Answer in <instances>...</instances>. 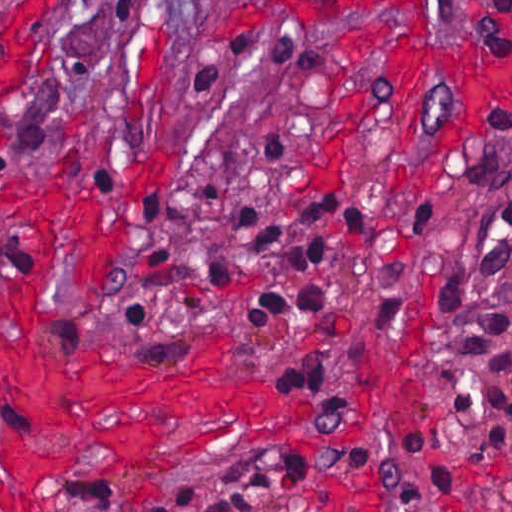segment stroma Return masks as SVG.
Returning <instances> with one entry per match:
<instances>
[{"label":"stroma","mask_w":512,"mask_h":512,"mask_svg":"<svg viewBox=\"0 0 512 512\" xmlns=\"http://www.w3.org/2000/svg\"><path fill=\"white\" fill-rule=\"evenodd\" d=\"M237 1L0 0V180L96 194L105 214L126 217L123 248L100 284L76 283L67 250L58 249L51 266L57 307L40 321L37 341L152 368L189 366L204 343L229 341L238 355L220 381L261 383L309 403L310 424L322 429L358 428L367 393L369 434L329 453L296 445L245 450L229 438L172 471L81 475L69 468L42 479L43 511L156 512L161 495L224 467L303 457L324 474L291 483L285 512H441L424 474L412 473L392 494L375 480L380 461L418 426L437 439L480 512H512V478L501 458L512 456V440L501 456L483 442L455 391V366L471 352L469 325L512 191V140L502 138L512 129V104L489 112L444 174L408 200L401 197L406 176L455 119L443 78L419 75L406 142L396 139L389 110L361 123L326 168L334 99L358 41L365 28L392 19L237 21L230 18ZM471 1L432 0L434 45L512 73V54H477L467 28ZM225 30L300 34L329 51L332 71L285 77L236 63L215 90L200 93L197 51ZM215 175L218 202L203 207L195 197ZM322 193L366 202V248L343 223L328 222L320 261L294 270L232 230L245 199L270 206ZM34 248L28 228L0 212V290L18 286ZM170 250L171 265L154 266ZM219 258L236 267L234 283L203 288ZM308 281L338 294L333 319L288 313L248 327L257 289L295 291ZM141 291L154 321L131 339L127 308ZM310 359L324 366L331 397L289 385L270 367Z\"/></svg>","instance_id":"obj_1"}]
</instances>
